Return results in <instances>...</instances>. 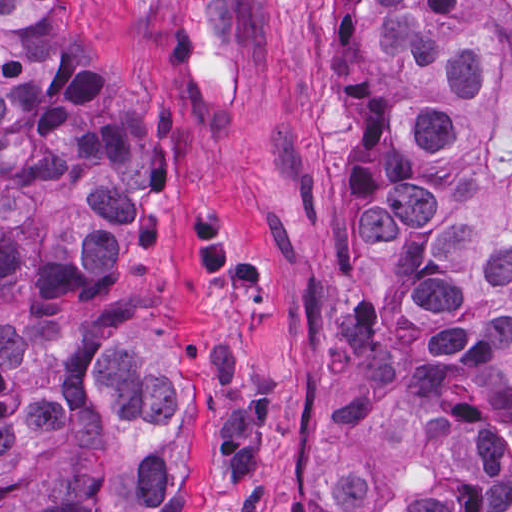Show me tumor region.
<instances>
[{
	"label": "tumor region",
	"mask_w": 512,
	"mask_h": 512,
	"mask_svg": "<svg viewBox=\"0 0 512 512\" xmlns=\"http://www.w3.org/2000/svg\"><path fill=\"white\" fill-rule=\"evenodd\" d=\"M349 133L325 512H512V0H324ZM136 112L71 0H0V512H189L130 310Z\"/></svg>",
	"instance_id": "1"
}]
</instances>
